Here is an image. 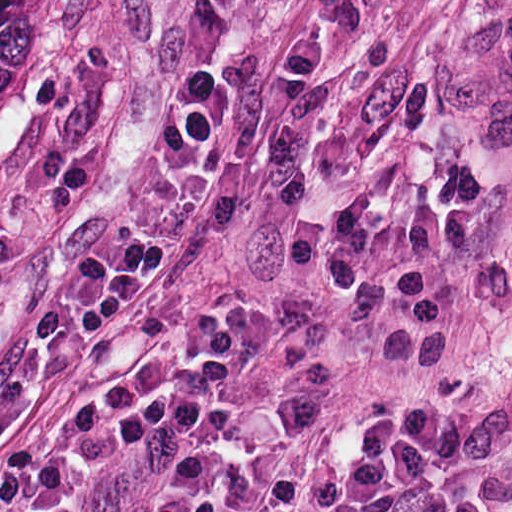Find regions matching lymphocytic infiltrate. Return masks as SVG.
<instances>
[{
    "mask_svg": "<svg viewBox=\"0 0 512 512\" xmlns=\"http://www.w3.org/2000/svg\"><path fill=\"white\" fill-rule=\"evenodd\" d=\"M237 104L228 78L190 74L171 99L166 184L145 229L44 272L24 334L0 364V447L53 365L142 290L178 239ZM255 340L253 311L215 303L198 316L191 362L119 366L0 460V512H97L146 443L166 452L165 468L138 512H203Z\"/></svg>",
    "mask_w": 512,
    "mask_h": 512,
    "instance_id": "f902f5d3",
    "label": "lymphocytic infiltrate"
}]
</instances>
